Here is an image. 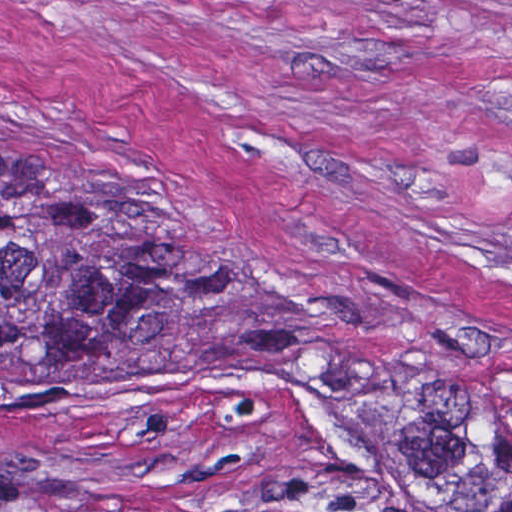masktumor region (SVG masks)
<instances>
[{
	"label": "tumor region",
	"mask_w": 512,
	"mask_h": 512,
	"mask_svg": "<svg viewBox=\"0 0 512 512\" xmlns=\"http://www.w3.org/2000/svg\"><path fill=\"white\" fill-rule=\"evenodd\" d=\"M226 288L142 210L90 188L0 200V359L79 380L202 352ZM394 498L422 512H512V391L441 363L304 342Z\"/></svg>",
	"instance_id": "1"
}]
</instances>
